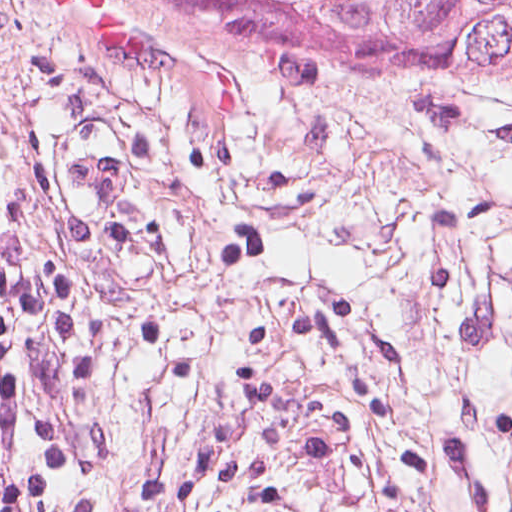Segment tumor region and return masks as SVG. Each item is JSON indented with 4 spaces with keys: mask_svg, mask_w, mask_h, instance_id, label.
Segmentation results:
<instances>
[{
    "mask_svg": "<svg viewBox=\"0 0 512 512\" xmlns=\"http://www.w3.org/2000/svg\"><path fill=\"white\" fill-rule=\"evenodd\" d=\"M289 77L339 67L412 93L512 88V0H164Z\"/></svg>",
    "mask_w": 512,
    "mask_h": 512,
    "instance_id": "tumor-region-1",
    "label": "tumor region"
}]
</instances>
